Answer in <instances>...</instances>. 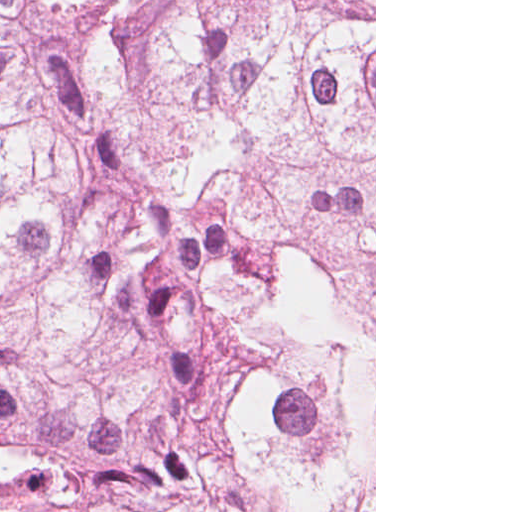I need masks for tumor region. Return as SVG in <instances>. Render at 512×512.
<instances>
[{
    "label": "tumor region",
    "mask_w": 512,
    "mask_h": 512,
    "mask_svg": "<svg viewBox=\"0 0 512 512\" xmlns=\"http://www.w3.org/2000/svg\"><path fill=\"white\" fill-rule=\"evenodd\" d=\"M373 228L0 95V512H282Z\"/></svg>",
    "instance_id": "e687c5a6"
}]
</instances>
